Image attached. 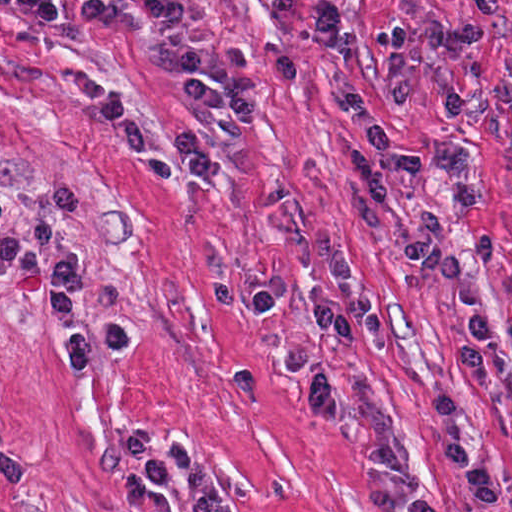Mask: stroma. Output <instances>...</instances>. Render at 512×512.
<instances>
[{
    "label": "stroma",
    "mask_w": 512,
    "mask_h": 512,
    "mask_svg": "<svg viewBox=\"0 0 512 512\" xmlns=\"http://www.w3.org/2000/svg\"><path fill=\"white\" fill-rule=\"evenodd\" d=\"M60 36L71 56L138 121L151 147L199 130L181 96V79L159 35L109 31L81 21L86 0H56ZM210 63L223 71L226 46L240 48L266 76L289 54L297 84L262 92L258 117L226 137L210 178L155 176L128 158L111 129L47 53L17 0H0V512H135L117 477L136 472L178 506L183 476L146 482L126 448L147 430L163 454L184 440L210 467L230 512H384L396 488L367 459L377 439L398 433L415 457V481L432 479L431 402L460 394L477 445L501 468V508L512 512V152L492 112L464 128L446 123L445 88L457 80L448 53L423 47L414 102L385 110L391 132L419 148L421 168L390 180L374 207L355 189L349 158L367 148L335 102L314 54L317 0L279 15L272 0H189ZM345 62L375 105L393 80L375 46L380 33L439 17L468 26L461 0H340ZM505 25L480 51L483 77L512 83V0H499ZM464 142L493 201L462 216L436 162ZM77 187L75 248L88 271V313L125 320L133 345L91 369H67L49 319L46 254L1 285V232L32 222L52 190ZM435 206L482 285L491 331V389H472L456 363L461 326L452 300L406 250L420 209ZM334 254L350 257L392 338L384 353L364 331L353 347L323 339V357L340 376L345 410L318 422L300 406L279 370L298 347L315 308L342 303ZM280 276L282 305L271 315L224 310L213 286L257 289ZM442 471L446 512H484L468 500L453 462Z\"/></svg>",
    "instance_id": "1"
}]
</instances>
